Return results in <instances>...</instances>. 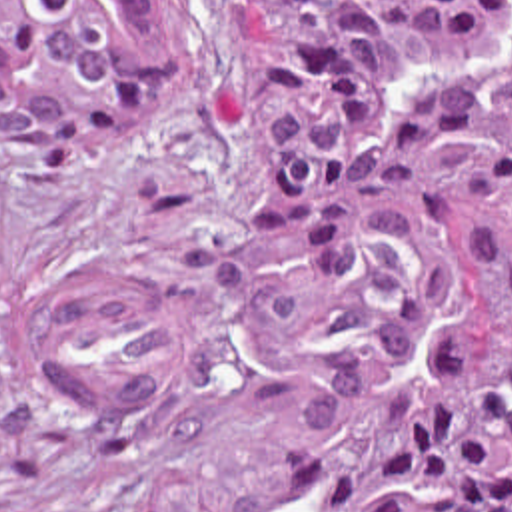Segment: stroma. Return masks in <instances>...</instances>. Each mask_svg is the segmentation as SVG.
<instances>
[{"label":"stroma","instance_id":"obj_1","mask_svg":"<svg viewBox=\"0 0 512 512\" xmlns=\"http://www.w3.org/2000/svg\"><path fill=\"white\" fill-rule=\"evenodd\" d=\"M266 150L242 0H178L174 80L134 130L72 166L0 152L18 264L0 348V512H280L282 424L342 326L330 270L236 212ZM78 264L178 290L174 372L134 412L76 408L40 378L36 312Z\"/></svg>","mask_w":512,"mask_h":512}]
</instances>
